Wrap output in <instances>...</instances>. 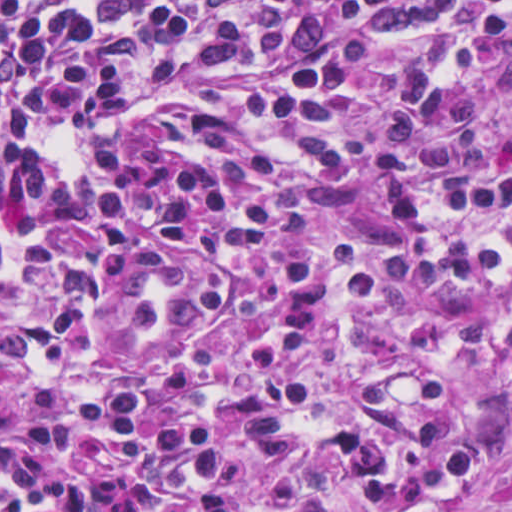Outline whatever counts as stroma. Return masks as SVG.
I'll return each instance as SVG.
<instances>
[{
    "label": "stroma",
    "mask_w": 512,
    "mask_h": 512,
    "mask_svg": "<svg viewBox=\"0 0 512 512\" xmlns=\"http://www.w3.org/2000/svg\"><path fill=\"white\" fill-rule=\"evenodd\" d=\"M444 36L475 47L477 83L494 102L512 91V33L474 28H445L427 40H398L371 71L349 114L351 159L337 178L324 180L265 130L245 119L237 108L244 87L259 79L251 70H228L189 90L167 95L154 109L127 128L64 133L55 138L67 158L66 178L58 185L48 214L34 222L0 221V242L20 257L39 241L67 244L70 227L100 187L108 140L131 138L175 148H196L186 124L200 113L220 112L219 153L230 170L272 194L273 234L266 247L297 254L312 243L345 238L363 250L377 270L387 257L393 234L381 198L378 154L382 122L394 85L416 58ZM373 327L349 329L339 340L326 379L305 404L303 426L337 430L352 420L357 389L376 367H442L467 377L476 399L456 439L496 461L492 474L470 493L463 512H512V387L496 369L477 365L459 346L454 312L417 313L396 301ZM304 512H362L347 499L316 500Z\"/></svg>",
    "instance_id": "1"
}]
</instances>
